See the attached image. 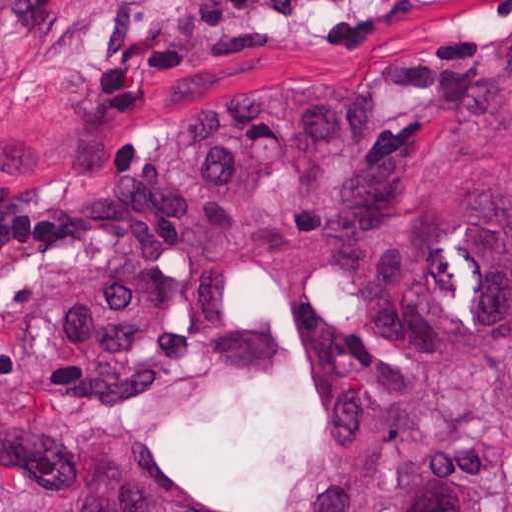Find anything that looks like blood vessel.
<instances>
[{
    "instance_id": "obj_1",
    "label": "blood vessel",
    "mask_w": 512,
    "mask_h": 512,
    "mask_svg": "<svg viewBox=\"0 0 512 512\" xmlns=\"http://www.w3.org/2000/svg\"><path fill=\"white\" fill-rule=\"evenodd\" d=\"M229 19H262L323 7L337 0H202Z\"/></svg>"
}]
</instances>
